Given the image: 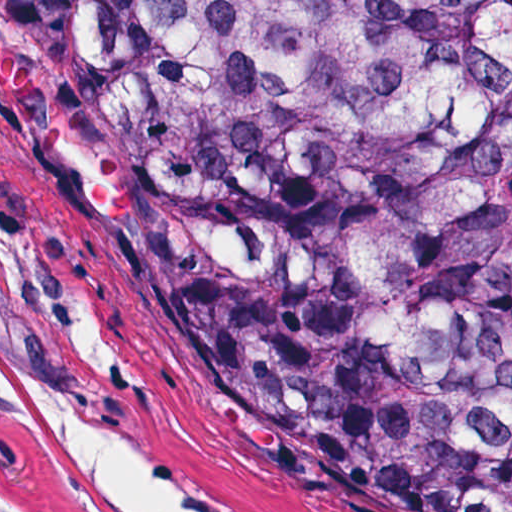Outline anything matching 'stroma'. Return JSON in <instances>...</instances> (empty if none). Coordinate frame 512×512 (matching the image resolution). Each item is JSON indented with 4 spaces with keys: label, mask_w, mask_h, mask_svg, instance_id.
<instances>
[{
    "label": "stroma",
    "mask_w": 512,
    "mask_h": 512,
    "mask_svg": "<svg viewBox=\"0 0 512 512\" xmlns=\"http://www.w3.org/2000/svg\"><path fill=\"white\" fill-rule=\"evenodd\" d=\"M0 336L143 432L227 512H407L193 320L0 245Z\"/></svg>",
    "instance_id": "stroma-1"
}]
</instances>
